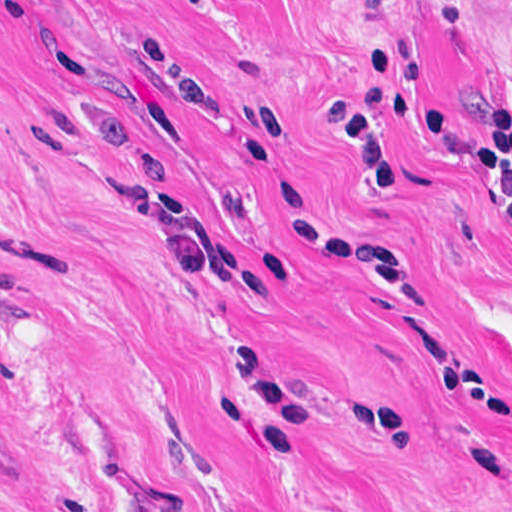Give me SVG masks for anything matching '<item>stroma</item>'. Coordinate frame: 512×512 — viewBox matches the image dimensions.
I'll use <instances>...</instances> for the list:
<instances>
[{
	"label": "stroma",
	"instance_id": "obj_1",
	"mask_svg": "<svg viewBox=\"0 0 512 512\" xmlns=\"http://www.w3.org/2000/svg\"><path fill=\"white\" fill-rule=\"evenodd\" d=\"M0 512H512V0H0Z\"/></svg>",
	"mask_w": 512,
	"mask_h": 512
}]
</instances>
